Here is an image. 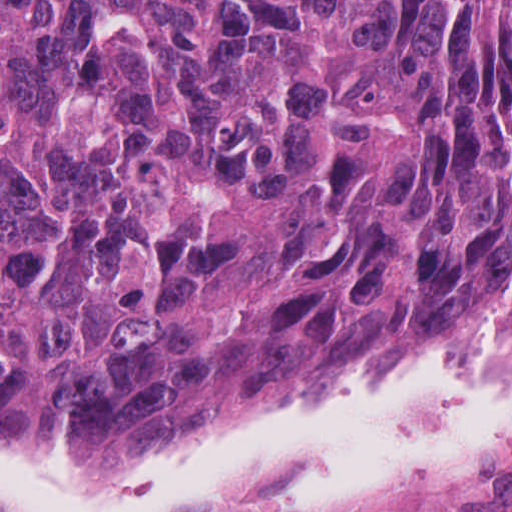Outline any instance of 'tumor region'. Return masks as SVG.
<instances>
[{"label": "tumor region", "instance_id": "tumor-region-1", "mask_svg": "<svg viewBox=\"0 0 512 512\" xmlns=\"http://www.w3.org/2000/svg\"><path fill=\"white\" fill-rule=\"evenodd\" d=\"M512 318V0H1V427L286 420Z\"/></svg>", "mask_w": 512, "mask_h": 512}]
</instances>
